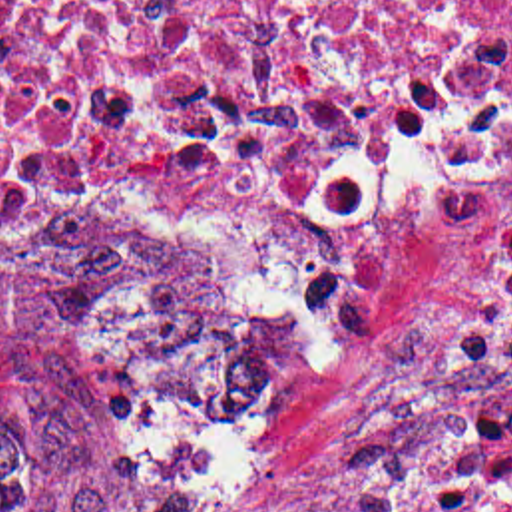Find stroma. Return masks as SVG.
Returning <instances> with one entry per match:
<instances>
[{"instance_id": "1", "label": "stroma", "mask_w": 512, "mask_h": 512, "mask_svg": "<svg viewBox=\"0 0 512 512\" xmlns=\"http://www.w3.org/2000/svg\"><path fill=\"white\" fill-rule=\"evenodd\" d=\"M512 203L485 215L408 223L396 292L374 346H320L290 302L230 245L205 241L294 332V410L284 462L240 512H412L428 468L503 388L469 370L461 322ZM91 229L0 243V480L57 508H135L181 490L173 430L105 362L47 290Z\"/></svg>"}]
</instances>
